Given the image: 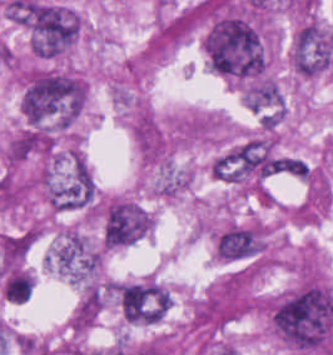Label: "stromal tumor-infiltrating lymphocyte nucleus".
I'll return each instance as SVG.
<instances>
[{"instance_id": "bc302bb0", "label": "stromal tumor-infiltrating lymphocyte nucleus", "mask_w": 333, "mask_h": 355, "mask_svg": "<svg viewBox=\"0 0 333 355\" xmlns=\"http://www.w3.org/2000/svg\"><path fill=\"white\" fill-rule=\"evenodd\" d=\"M0 287L12 304H22L32 293L33 281L26 271L17 267L1 275Z\"/></svg>"}]
</instances>
